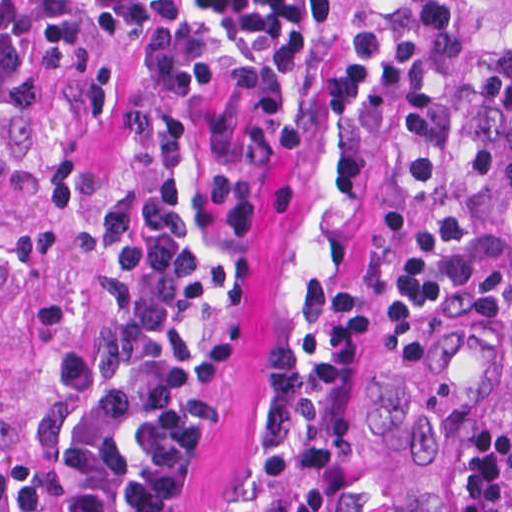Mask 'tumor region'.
<instances>
[{"label": "tumor region", "instance_id": "tumor-region-1", "mask_svg": "<svg viewBox=\"0 0 512 512\" xmlns=\"http://www.w3.org/2000/svg\"><path fill=\"white\" fill-rule=\"evenodd\" d=\"M448 39L372 112L383 313L341 512H512V0H445Z\"/></svg>", "mask_w": 512, "mask_h": 512}]
</instances>
